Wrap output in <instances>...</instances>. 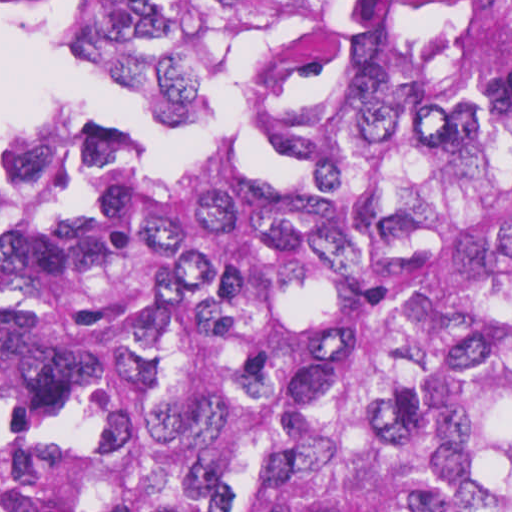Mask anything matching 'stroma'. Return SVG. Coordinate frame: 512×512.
<instances>
[{"mask_svg":"<svg viewBox=\"0 0 512 512\" xmlns=\"http://www.w3.org/2000/svg\"><path fill=\"white\" fill-rule=\"evenodd\" d=\"M35 1H89L80 10V36L87 17L100 4L119 1L205 23L238 46L269 48L285 39L321 34L351 24L383 4L401 15L410 33L445 23H475L486 1L512 0H0V3ZM11 140L0 139V154Z\"/></svg>","mask_w":512,"mask_h":512,"instance_id":"obj_1","label":"stroma"}]
</instances>
